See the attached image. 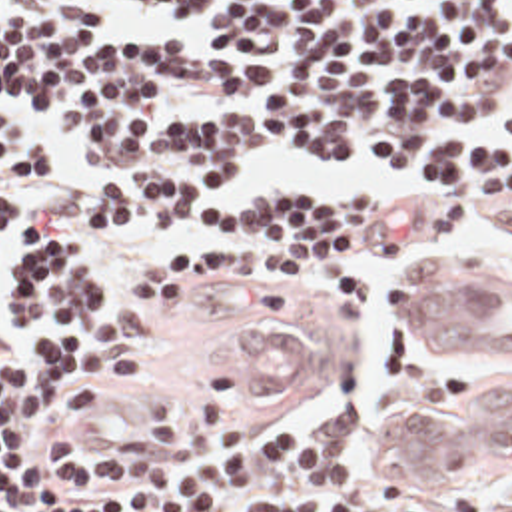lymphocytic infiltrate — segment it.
<instances>
[{
  "label": "lymphocytic infiltrate",
  "instance_id": "lymphocytic-infiltrate-1",
  "mask_svg": "<svg viewBox=\"0 0 512 512\" xmlns=\"http://www.w3.org/2000/svg\"><path fill=\"white\" fill-rule=\"evenodd\" d=\"M0 89L103 166L99 212L193 230L121 304L71 242L45 236L21 278L29 348L0 368L1 512H416V484L367 488L345 468L371 410L341 392L333 428L251 422L217 370L185 402L137 410L141 436L91 448L71 420L149 356L171 302L207 276L351 304L339 246L376 202H223L277 148H323L512 208V156L472 139L512 89V0H0ZM512 133V105L496 119ZM43 176L0 129V232Z\"/></svg>",
  "mask_w": 512,
  "mask_h": 512
}]
</instances>
